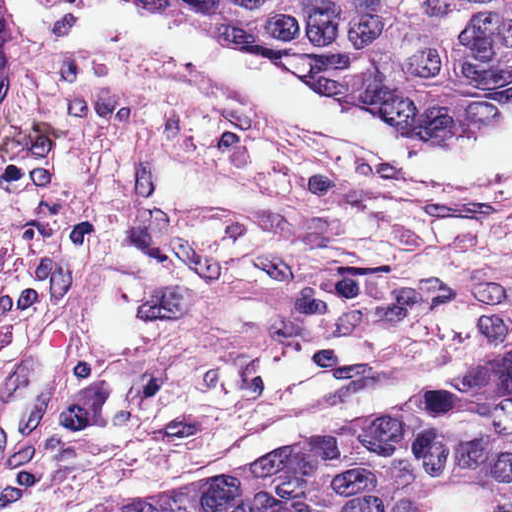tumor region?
<instances>
[{
  "label": "tumor region",
  "mask_w": 512,
  "mask_h": 512,
  "mask_svg": "<svg viewBox=\"0 0 512 512\" xmlns=\"http://www.w3.org/2000/svg\"><path fill=\"white\" fill-rule=\"evenodd\" d=\"M372 121L453 143L512 115V0H174ZM365 512H512V351L332 438Z\"/></svg>",
  "instance_id": "1"
}]
</instances>
